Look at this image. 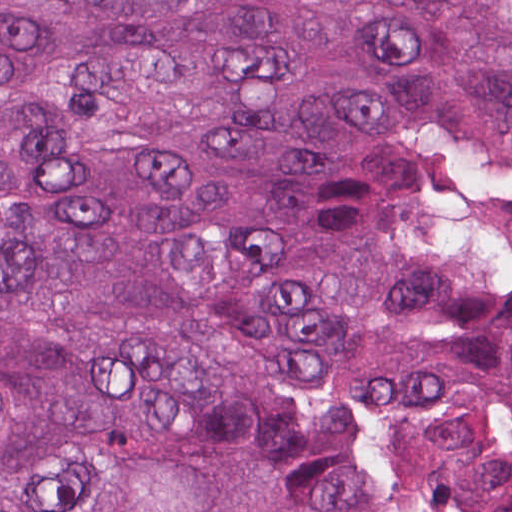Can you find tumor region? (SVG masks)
Wrapping results in <instances>:
<instances>
[{
	"label": "tumor region",
	"mask_w": 512,
	"mask_h": 512,
	"mask_svg": "<svg viewBox=\"0 0 512 512\" xmlns=\"http://www.w3.org/2000/svg\"><path fill=\"white\" fill-rule=\"evenodd\" d=\"M0 512H512V0H0Z\"/></svg>",
	"instance_id": "tumor-region-1"
}]
</instances>
